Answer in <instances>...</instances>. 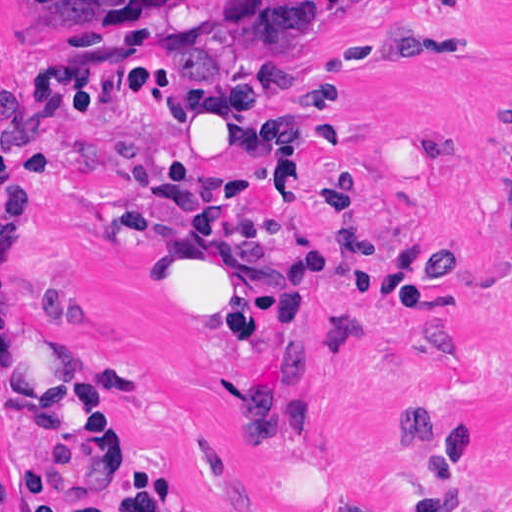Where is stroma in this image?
I'll list each match as a JSON object with an SVG mask.
<instances>
[{
    "mask_svg": "<svg viewBox=\"0 0 512 512\" xmlns=\"http://www.w3.org/2000/svg\"><path fill=\"white\" fill-rule=\"evenodd\" d=\"M206 1L0 0V512H512V0L190 77ZM165 228L260 250L256 318L112 294Z\"/></svg>",
    "mask_w": 512,
    "mask_h": 512,
    "instance_id": "35a3bbf8",
    "label": "stroma"
}]
</instances>
